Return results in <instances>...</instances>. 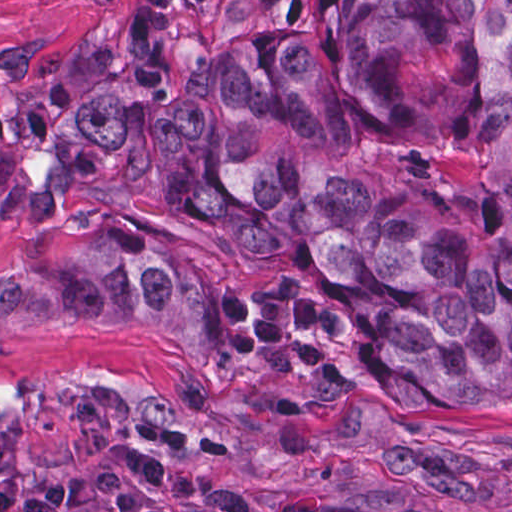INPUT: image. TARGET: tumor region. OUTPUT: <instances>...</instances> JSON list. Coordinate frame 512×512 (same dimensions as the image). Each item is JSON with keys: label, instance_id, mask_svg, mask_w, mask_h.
Segmentation results:
<instances>
[{"label": "tumor region", "instance_id": "1", "mask_svg": "<svg viewBox=\"0 0 512 512\" xmlns=\"http://www.w3.org/2000/svg\"><path fill=\"white\" fill-rule=\"evenodd\" d=\"M191 8L129 0L0 109V217L151 198L326 274L222 292L45 237L0 270V343L136 330L194 382L291 408L512 398V0H327L227 37H185Z\"/></svg>", "mask_w": 512, "mask_h": 512}]
</instances>
